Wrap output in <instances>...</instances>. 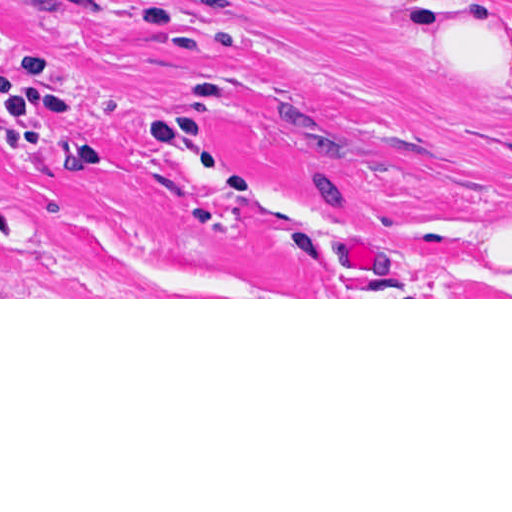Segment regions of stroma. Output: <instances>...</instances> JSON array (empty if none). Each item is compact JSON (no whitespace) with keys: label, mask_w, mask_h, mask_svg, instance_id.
Segmentation results:
<instances>
[{"label":"stroma","mask_w":512,"mask_h":512,"mask_svg":"<svg viewBox=\"0 0 512 512\" xmlns=\"http://www.w3.org/2000/svg\"><path fill=\"white\" fill-rule=\"evenodd\" d=\"M0 299H512V0H0Z\"/></svg>","instance_id":"1"}]
</instances>
